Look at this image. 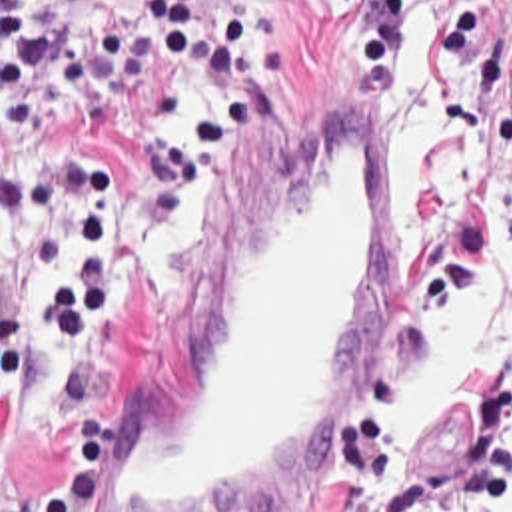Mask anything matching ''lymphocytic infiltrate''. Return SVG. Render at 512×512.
<instances>
[{
    "mask_svg": "<svg viewBox=\"0 0 512 512\" xmlns=\"http://www.w3.org/2000/svg\"><path fill=\"white\" fill-rule=\"evenodd\" d=\"M175 68L213 78L205 120L211 150L247 120L249 88L263 86L251 44V0H137ZM495 0H333V52L363 98L379 96L407 6L437 12L447 58L457 60ZM62 62V84L86 108L82 142L46 144L0 164V250L38 240V274L24 300L0 314V410L42 372L40 416L58 454L38 487L0 477V512H82L88 477L114 442V398L98 376L131 324L127 202L104 152L125 136L151 78L135 26L100 20L64 44V0H0V138L34 136L36 100ZM512 92V56H511ZM173 172L167 126L139 154V226Z\"/></svg>",
    "mask_w": 512,
    "mask_h": 512,
    "instance_id": "1",
    "label": "lymphocytic infiltrate"
}]
</instances>
